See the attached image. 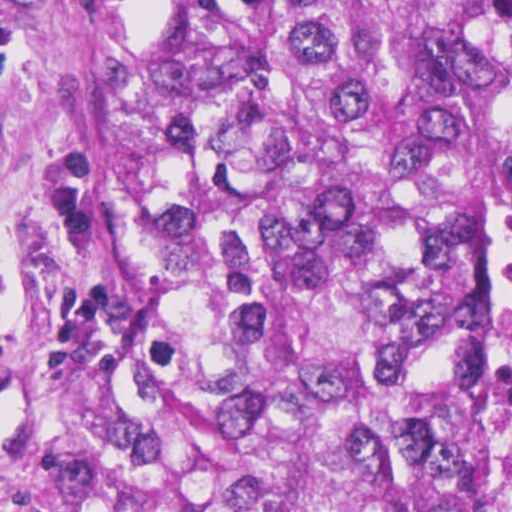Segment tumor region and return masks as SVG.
Returning a JSON list of instances; mask_svg holds the SVG:
<instances>
[{"mask_svg":"<svg viewBox=\"0 0 512 512\" xmlns=\"http://www.w3.org/2000/svg\"><path fill=\"white\" fill-rule=\"evenodd\" d=\"M49 512H453V0H145L115 444Z\"/></svg>","mask_w":512,"mask_h":512,"instance_id":"e687c5a6","label":"tumor region"}]
</instances>
